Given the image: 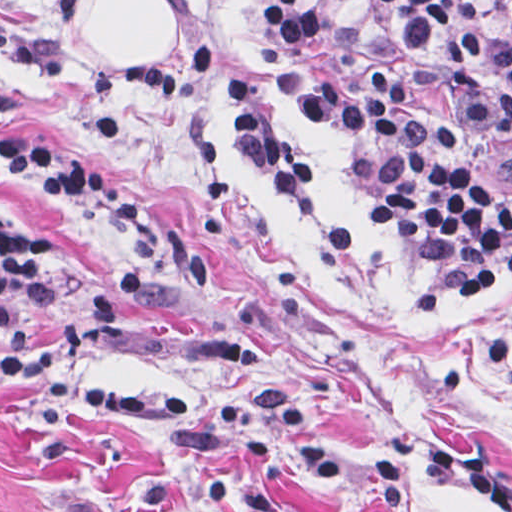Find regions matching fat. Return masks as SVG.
Returning <instances> with one entry per match:
<instances>
[{
    "mask_svg": "<svg viewBox=\"0 0 512 512\" xmlns=\"http://www.w3.org/2000/svg\"><path fill=\"white\" fill-rule=\"evenodd\" d=\"M169 11L163 0H82L86 43L108 67L147 52L171 59L177 55V24Z\"/></svg>",
    "mask_w": 512,
    "mask_h": 512,
    "instance_id": "53f6f03d",
    "label": "fat"
}]
</instances>
